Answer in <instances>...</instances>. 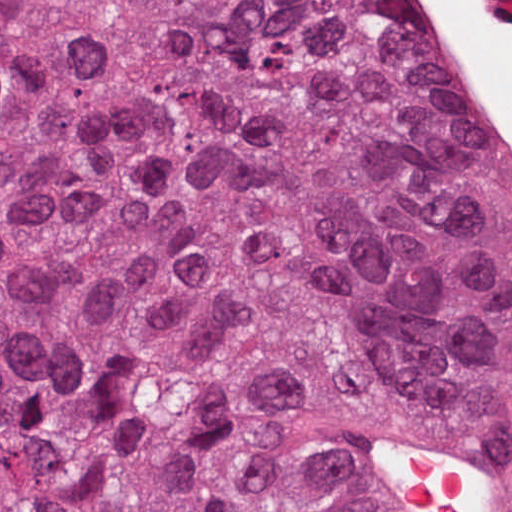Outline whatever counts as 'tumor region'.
I'll return each instance as SVG.
<instances>
[{"label": "tumor region", "instance_id": "1", "mask_svg": "<svg viewBox=\"0 0 512 512\" xmlns=\"http://www.w3.org/2000/svg\"><path fill=\"white\" fill-rule=\"evenodd\" d=\"M410 412L512 463V179L404 1H0V512H379Z\"/></svg>", "mask_w": 512, "mask_h": 512}]
</instances>
